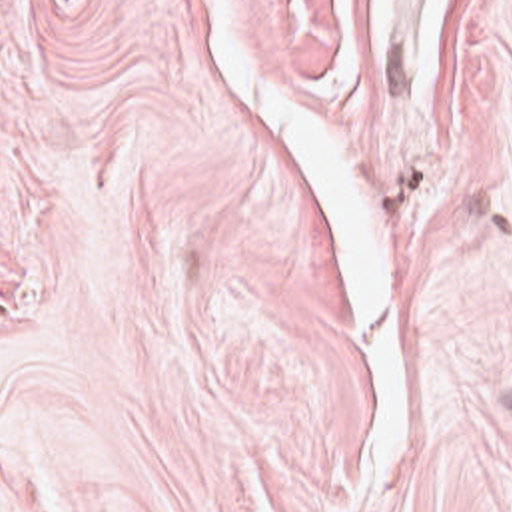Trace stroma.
Returning <instances> with one entry per match:
<instances>
[{
    "instance_id": "1",
    "label": "stroma",
    "mask_w": 512,
    "mask_h": 512,
    "mask_svg": "<svg viewBox=\"0 0 512 512\" xmlns=\"http://www.w3.org/2000/svg\"><path fill=\"white\" fill-rule=\"evenodd\" d=\"M0 512H512V0H0Z\"/></svg>"
}]
</instances>
